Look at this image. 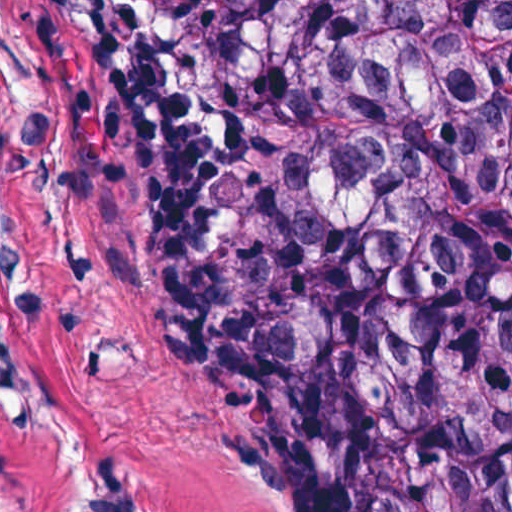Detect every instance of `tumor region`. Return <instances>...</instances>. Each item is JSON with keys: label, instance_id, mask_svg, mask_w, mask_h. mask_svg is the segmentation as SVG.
I'll use <instances>...</instances> for the list:
<instances>
[{"label": "tumor region", "instance_id": "e687c5a6", "mask_svg": "<svg viewBox=\"0 0 512 512\" xmlns=\"http://www.w3.org/2000/svg\"><path fill=\"white\" fill-rule=\"evenodd\" d=\"M210 390L295 512H512L485 225L512 52L454 1H173L94 59Z\"/></svg>", "mask_w": 512, "mask_h": 512}]
</instances>
